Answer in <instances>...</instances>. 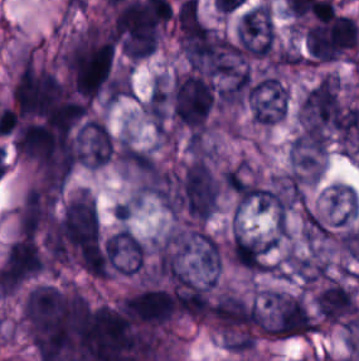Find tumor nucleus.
Returning a JSON list of instances; mask_svg holds the SVG:
<instances>
[{
  "label": "tumor nucleus",
  "mask_w": 359,
  "mask_h": 361,
  "mask_svg": "<svg viewBox=\"0 0 359 361\" xmlns=\"http://www.w3.org/2000/svg\"><path fill=\"white\" fill-rule=\"evenodd\" d=\"M274 34L270 8L266 3L244 11L236 25V39L244 48H269Z\"/></svg>",
  "instance_id": "obj_1"
}]
</instances>
